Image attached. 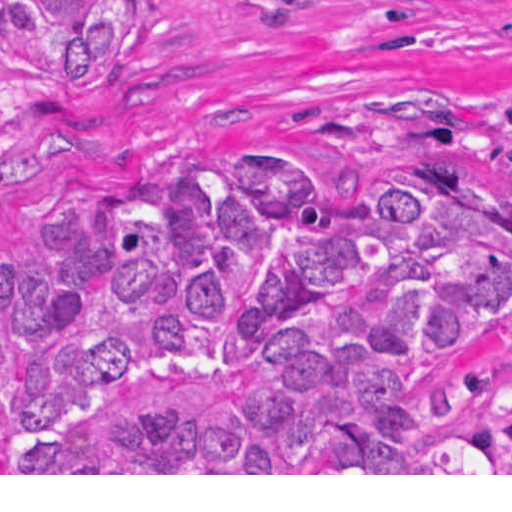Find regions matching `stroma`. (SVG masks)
Wrapping results in <instances>:
<instances>
[{
	"instance_id": "obj_1",
	"label": "stroma",
	"mask_w": 512,
	"mask_h": 512,
	"mask_svg": "<svg viewBox=\"0 0 512 512\" xmlns=\"http://www.w3.org/2000/svg\"><path fill=\"white\" fill-rule=\"evenodd\" d=\"M136 70L98 103H56L0 75V261L59 193L162 163L270 147L317 186L417 155L512 186L488 109L512 93V0H157ZM512 339V302L483 320ZM0 475H512L19 473Z\"/></svg>"
}]
</instances>
